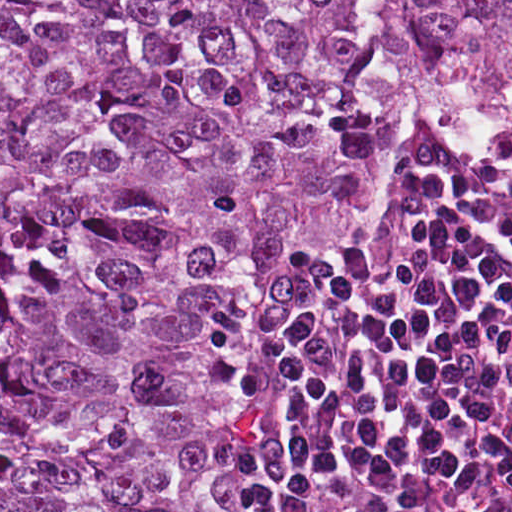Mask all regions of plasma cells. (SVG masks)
Instances as JSON below:
<instances>
[{
  "instance_id": "1",
  "label": "plasma cells",
  "mask_w": 512,
  "mask_h": 512,
  "mask_svg": "<svg viewBox=\"0 0 512 512\" xmlns=\"http://www.w3.org/2000/svg\"><path fill=\"white\" fill-rule=\"evenodd\" d=\"M252 512H512L510 147L411 153L369 252L271 281Z\"/></svg>"
}]
</instances>
